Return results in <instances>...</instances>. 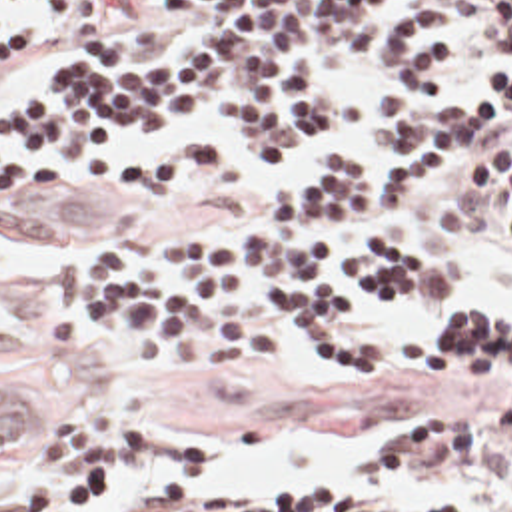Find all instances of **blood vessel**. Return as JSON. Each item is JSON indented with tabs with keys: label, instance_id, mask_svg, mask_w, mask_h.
I'll return each instance as SVG.
<instances>
[{
	"label": "blood vessel",
	"instance_id": "obj_1",
	"mask_svg": "<svg viewBox=\"0 0 512 512\" xmlns=\"http://www.w3.org/2000/svg\"><path fill=\"white\" fill-rule=\"evenodd\" d=\"M24 346V322L0 304V356ZM50 426V384L24 364H0V464L40 442Z\"/></svg>",
	"mask_w": 512,
	"mask_h": 512
}]
</instances>
